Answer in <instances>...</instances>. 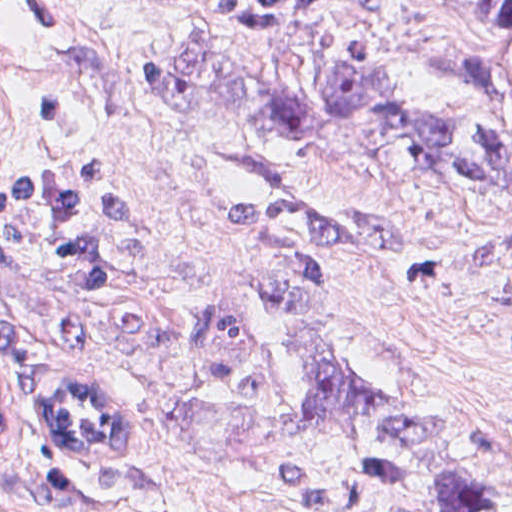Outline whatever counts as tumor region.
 I'll return each instance as SVG.
<instances>
[{"label":"tumor region","mask_w":512,"mask_h":512,"mask_svg":"<svg viewBox=\"0 0 512 512\" xmlns=\"http://www.w3.org/2000/svg\"><path fill=\"white\" fill-rule=\"evenodd\" d=\"M342 1H298L254 9L222 26L259 36L270 19H298ZM493 48L462 66L478 118L480 168L501 194L452 182L417 150L419 122L442 114L406 112L374 66L325 83L290 89L265 80L198 43L178 83L205 112L239 133L328 138L408 172L504 198L502 224L455 248L436 272L453 294L512 320V0H489ZM384 225L350 202H303L261 217L260 267L276 298L273 359L307 420L339 443L398 512H493V500L468 467L430 459L389 436L394 415H429L454 428L488 431L512 448V413L447 410L388 392L350 344L329 301V285L349 261L369 252Z\"/></svg>","instance_id":"obj_1"}]
</instances>
